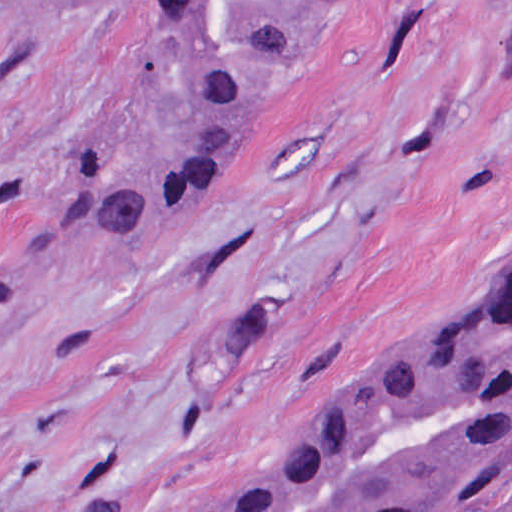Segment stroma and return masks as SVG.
Wrapping results in <instances>:
<instances>
[{
	"label": "stroma",
	"instance_id": "1",
	"mask_svg": "<svg viewBox=\"0 0 512 512\" xmlns=\"http://www.w3.org/2000/svg\"><path fill=\"white\" fill-rule=\"evenodd\" d=\"M161 126L123 1L0 0V197ZM511 277L500 1L329 0L187 225L0 307V512H209L304 411Z\"/></svg>",
	"mask_w": 512,
	"mask_h": 512
}]
</instances>
